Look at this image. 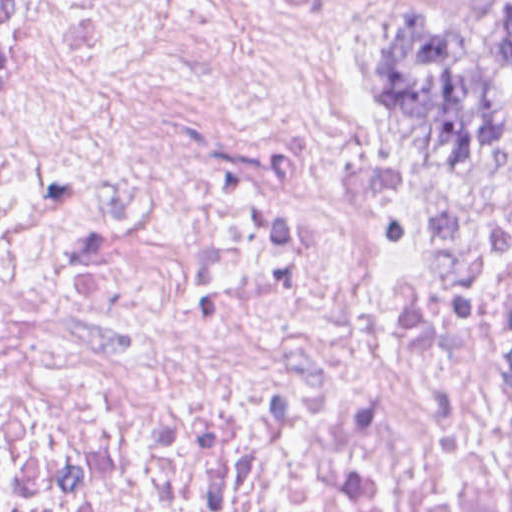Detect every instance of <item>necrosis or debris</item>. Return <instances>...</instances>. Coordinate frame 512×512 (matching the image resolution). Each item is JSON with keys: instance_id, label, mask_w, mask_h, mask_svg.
Listing matches in <instances>:
<instances>
[{"instance_id": "4bbe7bcc", "label": "necrosis or debris", "mask_w": 512, "mask_h": 512, "mask_svg": "<svg viewBox=\"0 0 512 512\" xmlns=\"http://www.w3.org/2000/svg\"><path fill=\"white\" fill-rule=\"evenodd\" d=\"M0 512H512V216L393 191L239 0H0Z\"/></svg>"}]
</instances>
